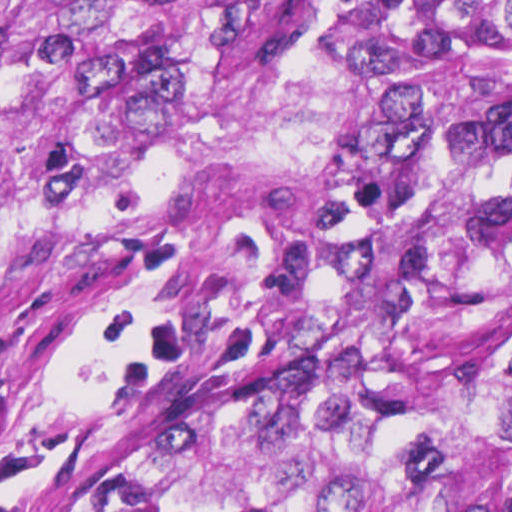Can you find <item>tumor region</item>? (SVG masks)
I'll return each mask as SVG.
<instances>
[{
    "label": "tumor region",
    "mask_w": 512,
    "mask_h": 512,
    "mask_svg": "<svg viewBox=\"0 0 512 512\" xmlns=\"http://www.w3.org/2000/svg\"><path fill=\"white\" fill-rule=\"evenodd\" d=\"M60 239L248 305L48 512H512V0H0V269Z\"/></svg>",
    "instance_id": "1"
}]
</instances>
